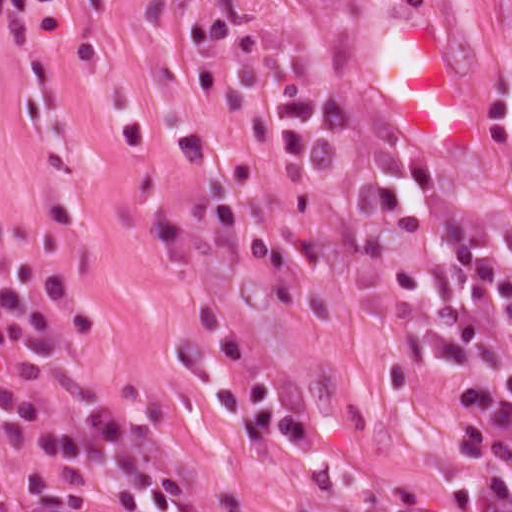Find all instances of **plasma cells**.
Returning a JSON list of instances; mask_svg holds the SVG:
<instances>
[{
  "label": "plasma cells",
  "instance_id": "9512152a",
  "mask_svg": "<svg viewBox=\"0 0 512 512\" xmlns=\"http://www.w3.org/2000/svg\"><path fill=\"white\" fill-rule=\"evenodd\" d=\"M237 92L265 97L273 110V155L279 168H324L348 128L345 115L309 95L287 65L267 49L248 47L227 24L202 33ZM487 137L512 132V81L504 82L483 122ZM424 194V211L379 183L357 187L348 231L364 259L384 272L398 333L393 378L415 388L427 359L456 374L481 366L484 378L451 383L447 399L485 411L512 400V360L465 313H429L420 304L427 285L420 271L392 252L396 230L416 232L434 219L437 196L458 204L441 218L444 259L456 291L477 305H499L512 322V261L494 247L488 210L448 192L425 161L410 162ZM506 183L512 191V174ZM68 317L83 331L94 316L71 272L23 258L0 277V352L27 349L66 357ZM455 489L447 499L415 490L383 492L359 512H512V421L489 422L447 469ZM0 512H198L175 469L167 437L151 411L122 402L107 408L63 405L0 432Z\"/></svg>",
  "mask_w": 512,
  "mask_h": 512
}]
</instances>
